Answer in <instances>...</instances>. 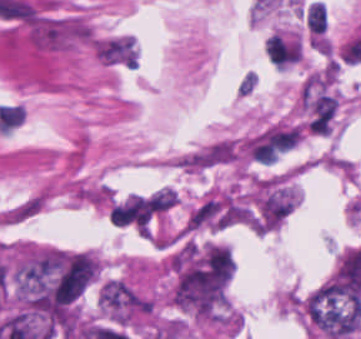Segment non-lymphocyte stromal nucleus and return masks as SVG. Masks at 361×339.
I'll return each mask as SVG.
<instances>
[{"instance_id":"1","label":"non-lymphocyte stromal nucleus","mask_w":361,"mask_h":339,"mask_svg":"<svg viewBox=\"0 0 361 339\" xmlns=\"http://www.w3.org/2000/svg\"><path fill=\"white\" fill-rule=\"evenodd\" d=\"M242 148L233 136H219L174 155L173 165L187 174H202L238 161Z\"/></svg>"},{"instance_id":"2","label":"non-lymphocyte stromal nucleus","mask_w":361,"mask_h":339,"mask_svg":"<svg viewBox=\"0 0 361 339\" xmlns=\"http://www.w3.org/2000/svg\"><path fill=\"white\" fill-rule=\"evenodd\" d=\"M47 201L48 193L41 189L1 213L0 219L9 225L20 224L40 211Z\"/></svg>"}]
</instances>
